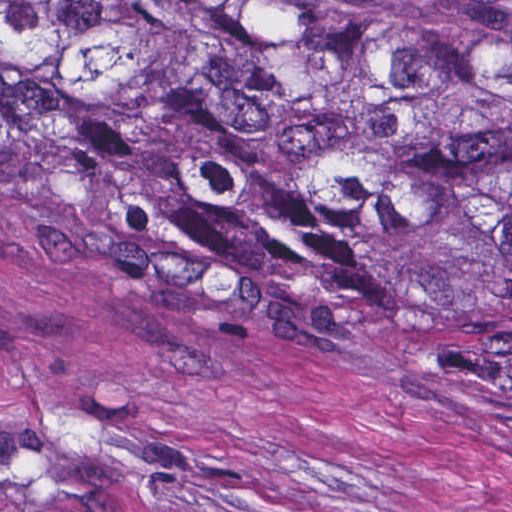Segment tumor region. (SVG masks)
I'll return each instance as SVG.
<instances>
[{"instance_id":"tumor-region-1","label":"tumor region","mask_w":512,"mask_h":512,"mask_svg":"<svg viewBox=\"0 0 512 512\" xmlns=\"http://www.w3.org/2000/svg\"><path fill=\"white\" fill-rule=\"evenodd\" d=\"M1 185L214 319L512 387V32L424 0H1Z\"/></svg>"}]
</instances>
